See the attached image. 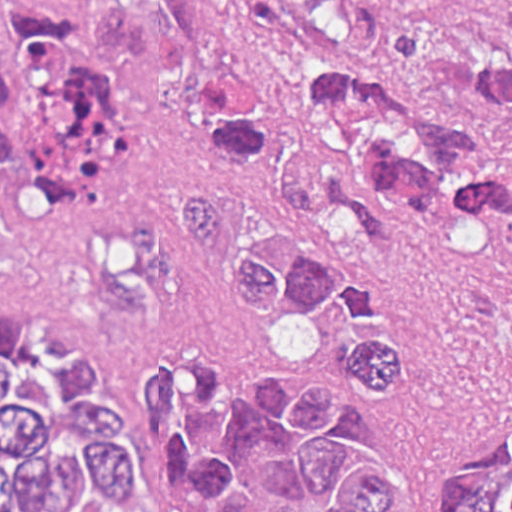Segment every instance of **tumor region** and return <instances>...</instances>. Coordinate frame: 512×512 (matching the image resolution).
Segmentation results:
<instances>
[{
	"label": "tumor region",
	"mask_w": 512,
	"mask_h": 512,
	"mask_svg": "<svg viewBox=\"0 0 512 512\" xmlns=\"http://www.w3.org/2000/svg\"><path fill=\"white\" fill-rule=\"evenodd\" d=\"M255 65L199 95L196 133L228 182L184 190L180 233L97 235L83 274L102 309L145 313L141 419L175 512H255L256 484L297 441L326 510L275 489L261 512H392L403 475L353 453L344 383L239 367L205 310L225 281L253 308L342 324L338 364L410 388L414 320L378 284L301 250L327 210L378 242V201L430 214L470 202L512 258V151L425 97L469 86L512 142V0H220ZM187 54L172 21L106 0H0V273L7 214L119 189L131 129L113 78L166 79ZM0 512H160L133 411L103 353L49 313H0ZM441 512H512V445L458 471Z\"/></svg>",
	"instance_id": "1"
}]
</instances>
